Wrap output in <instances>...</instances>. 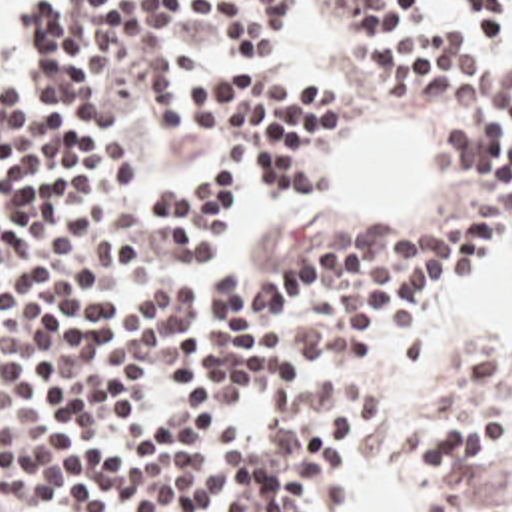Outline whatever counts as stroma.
<instances>
[{
  "label": "stroma",
  "instance_id": "35a3bbf8",
  "mask_svg": "<svg viewBox=\"0 0 512 512\" xmlns=\"http://www.w3.org/2000/svg\"><path fill=\"white\" fill-rule=\"evenodd\" d=\"M273 2L283 8V48H285V0H273ZM409 18H451L465 34H469V36H471L475 42H479L483 48H487L489 52H493L495 56H499L501 60H505L512 68V20H509V32H507L499 42H487V40L481 36V32L467 20V16H465L463 10L459 8L457 0H413V8H411V12L407 14V18L403 20V24H405ZM275 76L281 78V80L295 82V84H299V86L311 88V86H307V84H303V82L291 78V76L283 70V62H281V66L277 68ZM325 94H329V92H325ZM329 96L337 98L339 102H343L347 108H351V110L357 114L355 102H351V100H347V98H341V96H337V94H329ZM397 110L415 116V118L421 122V126L427 130V134L433 138V142H435V146H437V150H439V120H435V118L431 116V112H429V104H427V86L415 90L413 98H411L409 102H405L403 106H399ZM353 128H355V126H351V128H347V130H341V132H337V134L331 138V164L335 162V158H337V154H339L343 142H345L347 136L353 132ZM303 218H309V216L291 218V220H285V222H281V224L269 228L267 234H265V238H263V242H261V246H259L257 252H255L253 264H251L247 270H235V268H231V270H233V282H235V284H243L245 280H249V278H253L255 274L263 272L265 266H267V262H269V258L273 256L275 248H277L279 242L283 240L285 232H287L291 226H295L299 220H303ZM411 224H481V222H479V220L473 216V212L467 208V204H465L461 192H459L457 186L453 184V176L449 178V182H447L445 176H443V198L439 200L437 208H435L433 212H429V214H425V216L413 220ZM501 244L512 248L511 230H509L507 238H505ZM501 244H499V246H501ZM499 246H497V248H499ZM423 316H425V312H423ZM397 326H403V320H399L397 316L391 314V316L385 320V336H387V332H389L391 328H397ZM385 336H383V338H385ZM383 338H379L377 342H373V344H369V346H365V348H361V350H357V352H353V354H329V356H319V358H315V360H337V358L359 356V354H365V352H371V350L379 348V344H381ZM487 352H493V350H475V352L457 368V372L463 370V368H467V366H471L475 360H479V358H481L483 354H487ZM315 360H313V362H315ZM457 372H455V374H457ZM451 380H453V378H451ZM451 380H449V382H451ZM309 382H317V380L311 376V372H307V378H305L303 384H309ZM449 382H447V384H449ZM375 456H379L381 460H385L389 466L395 468L397 486H399V494H401V498H403L405 510H407V512H427V466H425V456H423V452H421V442H419V422H417L415 426H411V428L405 430V434H403L401 440L395 444V448H385L381 440L375 442V444H373L371 448H367V450H353V446H351V494H349L347 500L339 506L337 512H353V510H355V482H357L359 464H363V462H367V460H371V458H375ZM219 504H221V500H219L209 512H217V510H219Z\"/></svg>",
  "mask_w": 512,
  "mask_h": 512
}]
</instances>
